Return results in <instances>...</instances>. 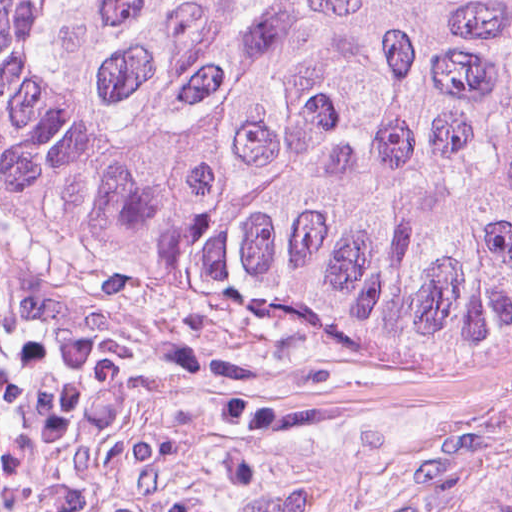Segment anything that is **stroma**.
<instances>
[{"label":"stroma","instance_id":"35a3bbf8","mask_svg":"<svg viewBox=\"0 0 512 512\" xmlns=\"http://www.w3.org/2000/svg\"><path fill=\"white\" fill-rule=\"evenodd\" d=\"M512 461V321L436 353L48 242L0 166L3 512H453Z\"/></svg>","mask_w":512,"mask_h":512}]
</instances>
